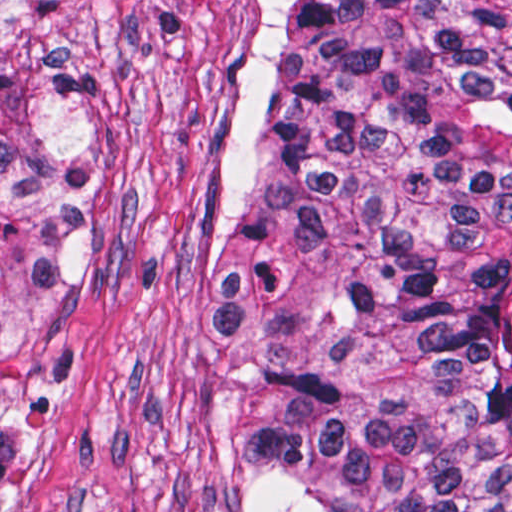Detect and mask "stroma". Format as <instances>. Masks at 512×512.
<instances>
[{
    "instance_id": "obj_1",
    "label": "stroma",
    "mask_w": 512,
    "mask_h": 512,
    "mask_svg": "<svg viewBox=\"0 0 512 512\" xmlns=\"http://www.w3.org/2000/svg\"><path fill=\"white\" fill-rule=\"evenodd\" d=\"M266 0H74L86 323L63 431L0 512H244L266 326L233 276V175Z\"/></svg>"
}]
</instances>
